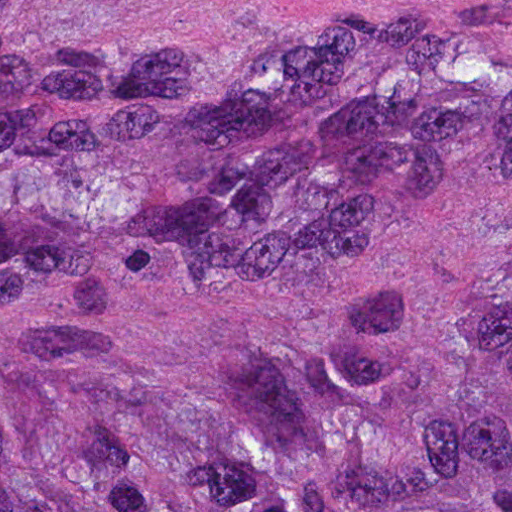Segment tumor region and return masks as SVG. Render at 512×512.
Segmentation results:
<instances>
[{
    "label": "tumor region",
    "instance_id": "e687c5a6",
    "mask_svg": "<svg viewBox=\"0 0 512 512\" xmlns=\"http://www.w3.org/2000/svg\"><path fill=\"white\" fill-rule=\"evenodd\" d=\"M0 512H512V0H0Z\"/></svg>",
    "mask_w": 512,
    "mask_h": 512
}]
</instances>
